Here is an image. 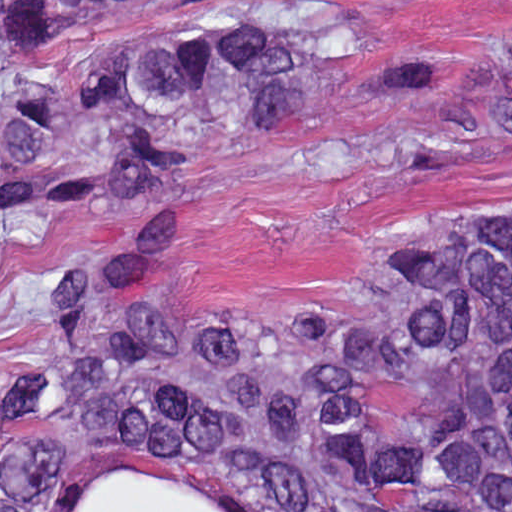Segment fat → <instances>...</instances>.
Returning <instances> with one entry per match:
<instances>
[{
    "mask_svg": "<svg viewBox=\"0 0 512 512\" xmlns=\"http://www.w3.org/2000/svg\"><path fill=\"white\" fill-rule=\"evenodd\" d=\"M79 512H234L219 502L161 475L126 467L91 479ZM411 512H449L427 507Z\"/></svg>",
    "mask_w": 512,
    "mask_h": 512,
    "instance_id": "1",
    "label": "fat"
}]
</instances>
